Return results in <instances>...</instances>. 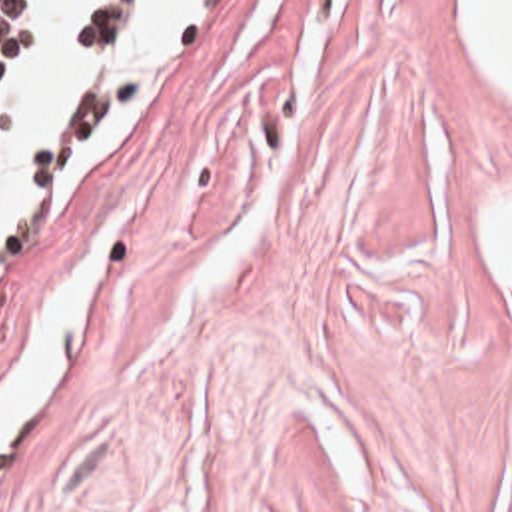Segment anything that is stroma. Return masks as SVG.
Returning <instances> with one entry per match:
<instances>
[{"label":"stroma","mask_w":512,"mask_h":512,"mask_svg":"<svg viewBox=\"0 0 512 512\" xmlns=\"http://www.w3.org/2000/svg\"><path fill=\"white\" fill-rule=\"evenodd\" d=\"M482 178L512 92L460 0H245L17 248L0 386L141 188L0 512H500L506 338L448 226Z\"/></svg>","instance_id":"obj_1"}]
</instances>
